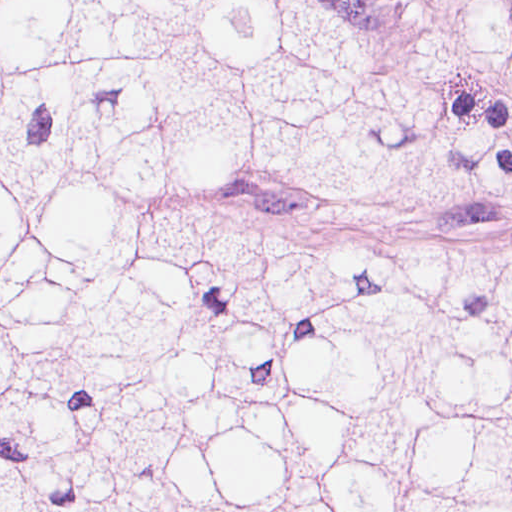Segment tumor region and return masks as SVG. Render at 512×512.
Listing matches in <instances>:
<instances>
[{"mask_svg":"<svg viewBox=\"0 0 512 512\" xmlns=\"http://www.w3.org/2000/svg\"><path fill=\"white\" fill-rule=\"evenodd\" d=\"M279 184L512 205V124L325 0H0V512H512V243L156 199Z\"/></svg>","mask_w":512,"mask_h":512,"instance_id":"1","label":"tumor region"}]
</instances>
